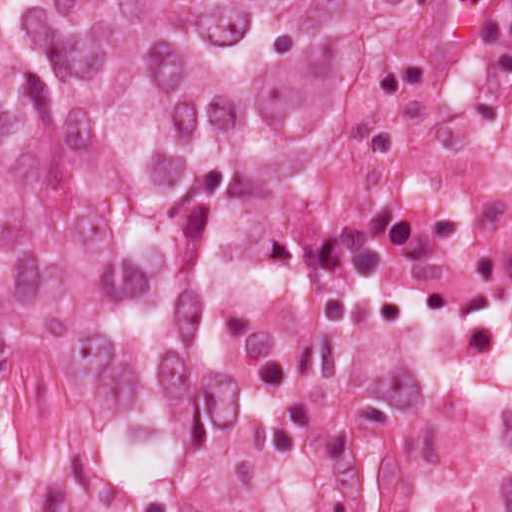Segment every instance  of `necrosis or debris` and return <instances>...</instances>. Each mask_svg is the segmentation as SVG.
I'll return each mask as SVG.
<instances>
[{
	"label": "necrosis or debris",
	"mask_w": 512,
	"mask_h": 512,
	"mask_svg": "<svg viewBox=\"0 0 512 512\" xmlns=\"http://www.w3.org/2000/svg\"><path fill=\"white\" fill-rule=\"evenodd\" d=\"M208 230L158 418L9 363V512H512V1H361L324 168Z\"/></svg>",
	"instance_id": "4bbe7bcc"
}]
</instances>
